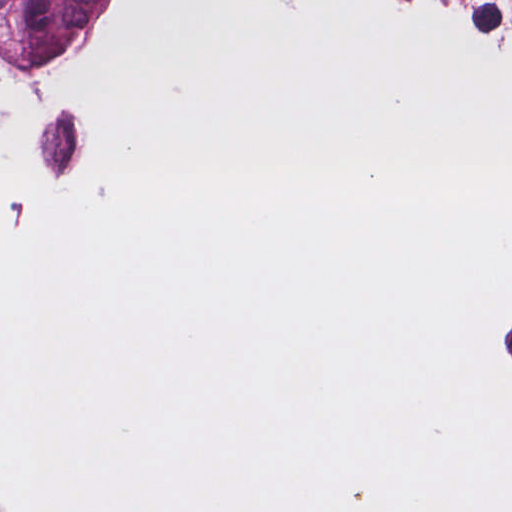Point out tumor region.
<instances>
[{
	"instance_id": "obj_1",
	"label": "tumor region",
	"mask_w": 512,
	"mask_h": 512,
	"mask_svg": "<svg viewBox=\"0 0 512 512\" xmlns=\"http://www.w3.org/2000/svg\"><path fill=\"white\" fill-rule=\"evenodd\" d=\"M136 0H0V69L92 78L129 38Z\"/></svg>"
}]
</instances>
